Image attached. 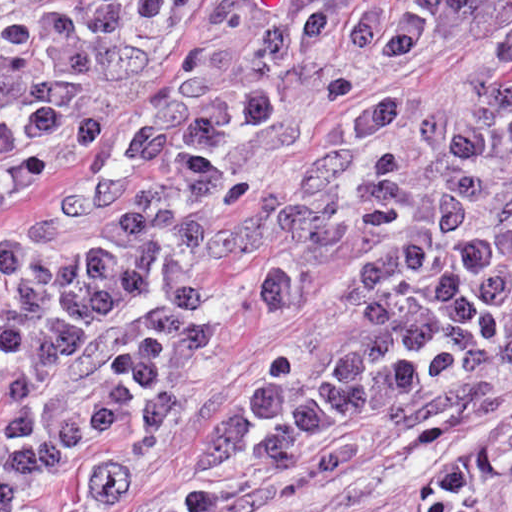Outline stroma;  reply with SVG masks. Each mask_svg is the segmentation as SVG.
Instances as JSON below:
<instances>
[{
  "label": "stroma",
  "instance_id": "1",
  "mask_svg": "<svg viewBox=\"0 0 512 512\" xmlns=\"http://www.w3.org/2000/svg\"><path fill=\"white\" fill-rule=\"evenodd\" d=\"M49 1L13 0L7 12L0 15V36L27 23ZM218 2L183 0L159 65L124 112L101 130L83 155L23 181L0 198V242L21 231L38 206L84 176L128 137L134 124L190 64ZM511 41L512 0L486 31L379 73L347 102L322 116L297 148L250 181L217 226L236 223L253 206L286 193L299 167L334 133V126L354 110L388 93L445 85L490 60ZM230 264L235 272L234 291L210 348L204 392L123 492L104 502L92 500L76 489L70 476L61 473L52 478L40 498L44 512H175L200 498L264 501L313 471L317 459L278 479H229L202 470L198 442L217 402L253 355L319 308L344 274L346 261H336L303 293L287 298L275 296L269 289L268 265L263 256H239ZM501 391L502 407L497 415L436 446L428 447L381 425H368L357 462L342 474L316 482L312 489L315 503L292 512H415L418 486L428 468L451 460L512 422V369L503 375Z\"/></svg>",
  "mask_w": 512,
  "mask_h": 512
}]
</instances>
